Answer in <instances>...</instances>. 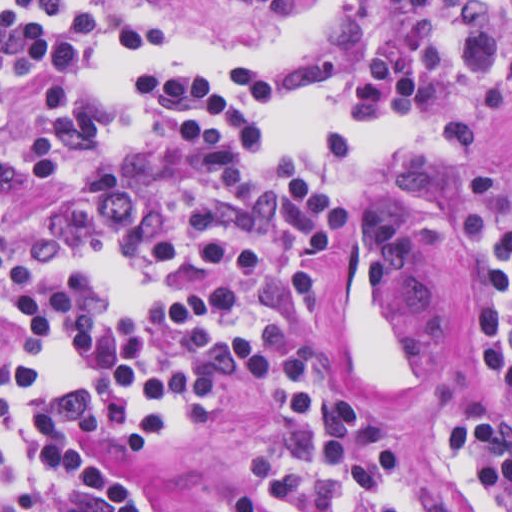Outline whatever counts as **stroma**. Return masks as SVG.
<instances>
[{
  "mask_svg": "<svg viewBox=\"0 0 512 512\" xmlns=\"http://www.w3.org/2000/svg\"><path fill=\"white\" fill-rule=\"evenodd\" d=\"M0 1H185L161 7L159 19L198 40H245L270 52L298 48L307 28L259 17L236 1H512V0H0ZM500 40L512 48V20ZM46 71L6 87L0 120V161L13 177L1 196L5 225H25L49 208L59 187L28 170L30 123L39 107ZM420 161L453 163L512 186V75L500 108L482 130L461 137L410 144L366 175L345 201L337 233L317 253L321 291L309 313L276 333L262 370L246 384L245 405L220 404L214 422L195 430L176 454L149 457L115 450L107 458L127 479L153 491L169 512H231L233 500L255 481V450L281 423L276 387L285 357L301 348L324 349L329 367L351 389L391 419L383 388L362 375L346 343V297L354 274L361 220L378 193L401 205L406 243V289L395 302L406 339V375L399 405L422 398H449L484 405L512 427V404L486 373L466 322L462 277L436 246L414 198ZM410 454L439 494L460 512H473L469 491L441 449L430 421L415 414Z\"/></svg>",
  "mask_w": 512,
  "mask_h": 512,
  "instance_id": "35a3bbf8",
  "label": "stroma"
}]
</instances>
